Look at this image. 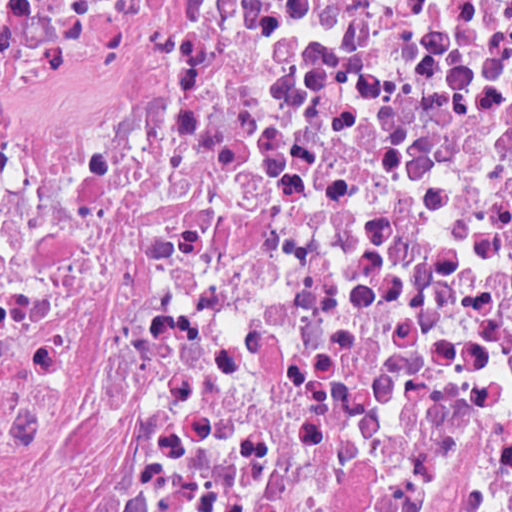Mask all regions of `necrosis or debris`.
I'll return each mask as SVG.
<instances>
[{
  "instance_id": "necrosis-or-debris-1",
  "label": "necrosis or debris",
  "mask_w": 512,
  "mask_h": 512,
  "mask_svg": "<svg viewBox=\"0 0 512 512\" xmlns=\"http://www.w3.org/2000/svg\"><path fill=\"white\" fill-rule=\"evenodd\" d=\"M0 512H512V0H0Z\"/></svg>"
}]
</instances>
